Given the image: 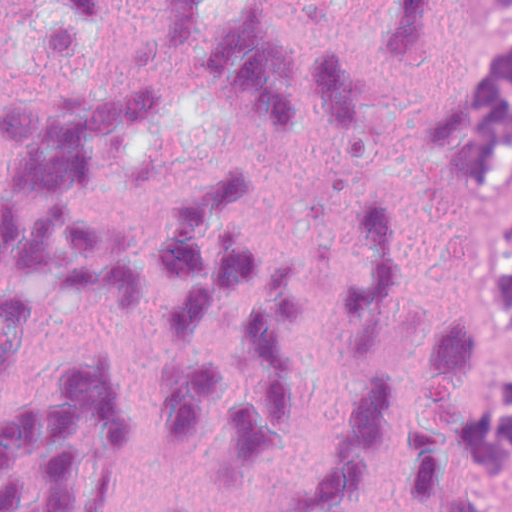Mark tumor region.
Segmentation results:
<instances>
[{
    "instance_id": "tumor-region-1",
    "label": "tumor region",
    "mask_w": 512,
    "mask_h": 512,
    "mask_svg": "<svg viewBox=\"0 0 512 512\" xmlns=\"http://www.w3.org/2000/svg\"><path fill=\"white\" fill-rule=\"evenodd\" d=\"M507 145L510 163L512 160V75L507 80ZM501 301L502 312L512 330V216L509 219L507 245L501 276L495 288ZM492 339V337H491ZM493 343V341H492ZM494 348V346H493ZM495 353V351H494ZM496 358V356H495ZM498 370L504 381L511 410V450H512V367L496 359ZM504 512H512L505 506Z\"/></svg>"
}]
</instances>
